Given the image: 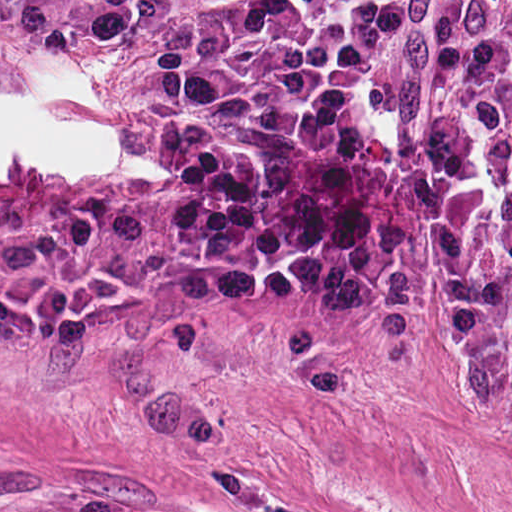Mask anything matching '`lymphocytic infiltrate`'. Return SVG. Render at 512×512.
<instances>
[{"mask_svg": "<svg viewBox=\"0 0 512 512\" xmlns=\"http://www.w3.org/2000/svg\"><path fill=\"white\" fill-rule=\"evenodd\" d=\"M171 0H0L35 52L101 49ZM411 0H199L174 13L149 142L190 219L187 290L234 298L279 279L302 241L312 163L387 80ZM439 73L512 92V0H442ZM433 245L434 357L451 395L512 423V123L440 112L405 150Z\"/></svg>", "mask_w": 512, "mask_h": 512, "instance_id": "f902f5d3", "label": "lymphocytic infiltrate"}]
</instances>
